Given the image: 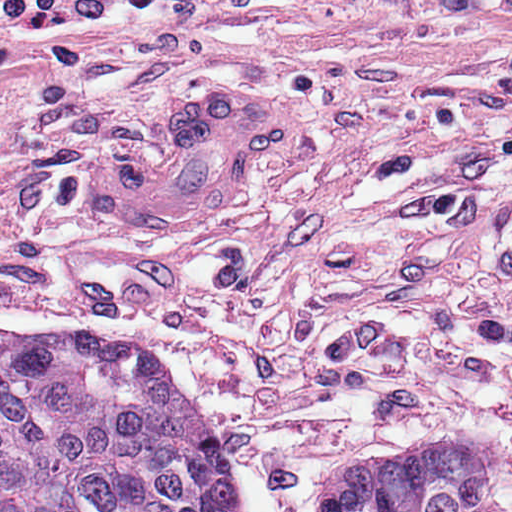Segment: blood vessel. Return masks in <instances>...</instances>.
<instances>
[{"instance_id":"1","label":"blood vessel","mask_w":512,"mask_h":512,"mask_svg":"<svg viewBox=\"0 0 512 512\" xmlns=\"http://www.w3.org/2000/svg\"><path fill=\"white\" fill-rule=\"evenodd\" d=\"M295 140L294 100L278 92L202 93L167 110L149 135L87 145L78 183L113 226L195 234L231 216Z\"/></svg>"}]
</instances>
